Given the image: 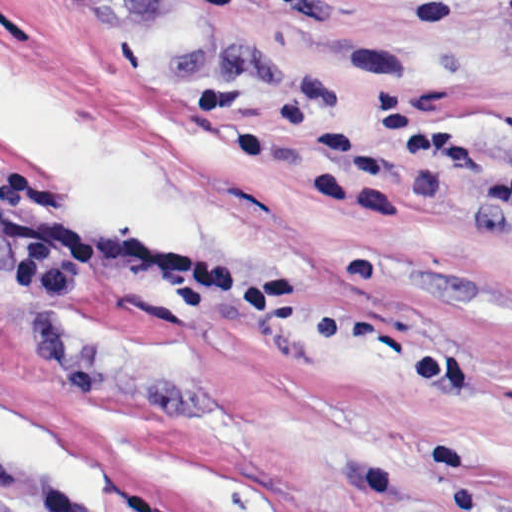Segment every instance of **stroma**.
I'll use <instances>...</instances> for the list:
<instances>
[{
  "label": "stroma",
  "instance_id": "obj_1",
  "mask_svg": "<svg viewBox=\"0 0 512 512\" xmlns=\"http://www.w3.org/2000/svg\"><path fill=\"white\" fill-rule=\"evenodd\" d=\"M0 0V490L15 512H512V231L410 171L317 201L264 122L393 99L512 168V0Z\"/></svg>",
  "mask_w": 512,
  "mask_h": 512
}]
</instances>
